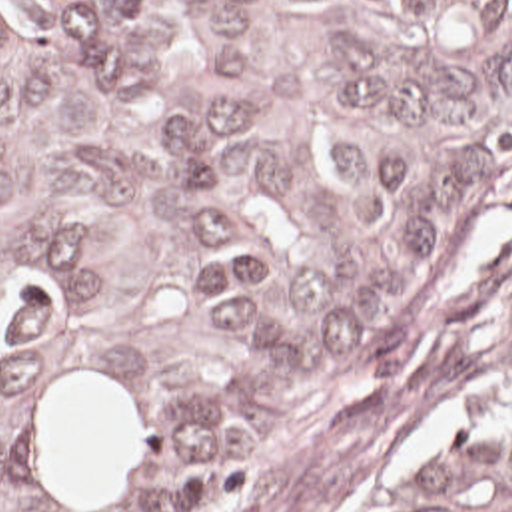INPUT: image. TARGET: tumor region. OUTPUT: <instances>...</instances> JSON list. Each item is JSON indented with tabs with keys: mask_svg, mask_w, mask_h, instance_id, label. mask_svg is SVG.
Wrapping results in <instances>:
<instances>
[{
	"mask_svg": "<svg viewBox=\"0 0 512 512\" xmlns=\"http://www.w3.org/2000/svg\"><path fill=\"white\" fill-rule=\"evenodd\" d=\"M512 177V0H0V512H253ZM357 512H512V385Z\"/></svg>",
	"mask_w": 512,
	"mask_h": 512,
	"instance_id": "tumor-region-1",
	"label": "tumor region"
}]
</instances>
